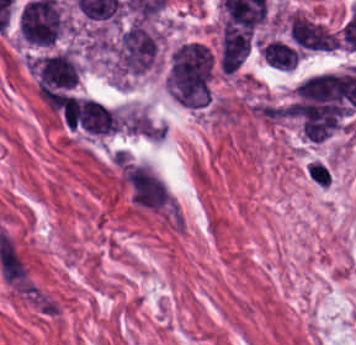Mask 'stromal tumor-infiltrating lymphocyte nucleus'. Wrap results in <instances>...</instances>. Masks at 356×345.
I'll list each match as a JSON object with an SVG mask.
<instances>
[{
  "label": "stromal tumor-infiltrating lymphocyte nucleus",
  "mask_w": 356,
  "mask_h": 345,
  "mask_svg": "<svg viewBox=\"0 0 356 345\" xmlns=\"http://www.w3.org/2000/svg\"><path fill=\"white\" fill-rule=\"evenodd\" d=\"M310 179L321 187H329L331 174L329 166L324 162L312 161L308 167Z\"/></svg>",
  "instance_id": "bc302bb0"
}]
</instances>
